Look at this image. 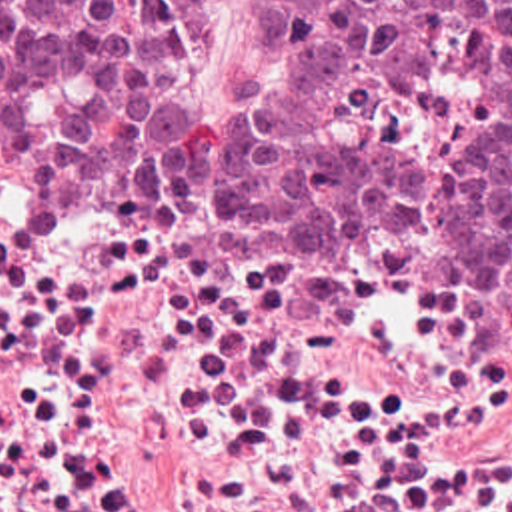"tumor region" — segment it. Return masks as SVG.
Returning <instances> with one entry per match:
<instances>
[{
    "label": "tumor region",
    "mask_w": 512,
    "mask_h": 512,
    "mask_svg": "<svg viewBox=\"0 0 512 512\" xmlns=\"http://www.w3.org/2000/svg\"><path fill=\"white\" fill-rule=\"evenodd\" d=\"M210 0H0V92L136 202L446 258L512 316V0H258L278 68L190 94Z\"/></svg>",
    "instance_id": "obj_1"
}]
</instances>
